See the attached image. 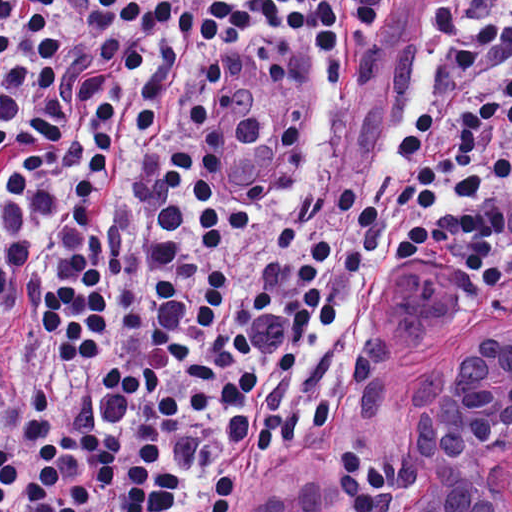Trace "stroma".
Masks as SVG:
<instances>
[{
	"instance_id": "35a3bbf8",
	"label": "stroma",
	"mask_w": 512,
	"mask_h": 512,
	"mask_svg": "<svg viewBox=\"0 0 512 512\" xmlns=\"http://www.w3.org/2000/svg\"><path fill=\"white\" fill-rule=\"evenodd\" d=\"M435 2L411 0L397 20L383 27L363 30L355 43V62L347 81L332 85H326V52L302 36H283L254 46L242 61L218 66L212 52L203 44L175 33L150 29L149 73L163 88L240 85L256 96L286 99L327 119L342 117L390 76L414 29ZM112 91L106 85L97 84L88 100L41 147L0 165V233L3 185L14 165L45 150ZM414 261L424 272L440 270L472 305L480 309L502 306L505 313H512V283L492 295H477L440 267L434 250L417 252L395 262L356 295L314 373L311 388L327 390L334 399V415L305 431L299 445L288 453L264 461L237 479V495L230 512H247L252 498L281 480L295 460L338 422L350 377L364 356L377 319L384 311V293L397 272ZM410 468L411 396L410 454L382 428L353 433L324 467L314 512H393L407 487Z\"/></svg>"
}]
</instances>
